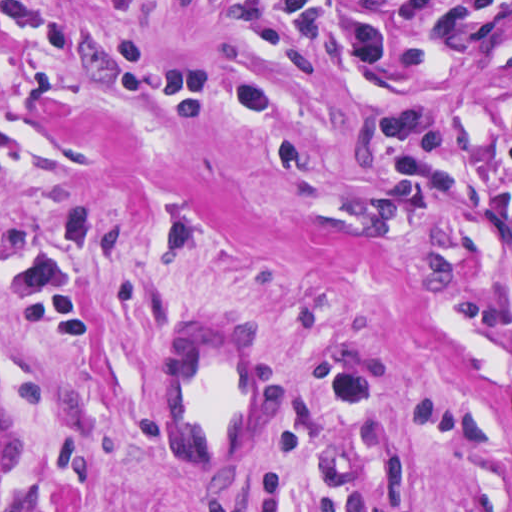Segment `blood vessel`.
<instances>
[{"mask_svg": "<svg viewBox=\"0 0 512 512\" xmlns=\"http://www.w3.org/2000/svg\"><path fill=\"white\" fill-rule=\"evenodd\" d=\"M228 309L191 315L163 365V413L183 475L236 474L275 426L283 355Z\"/></svg>", "mask_w": 512, "mask_h": 512, "instance_id": "1", "label": "blood vessel"}]
</instances>
